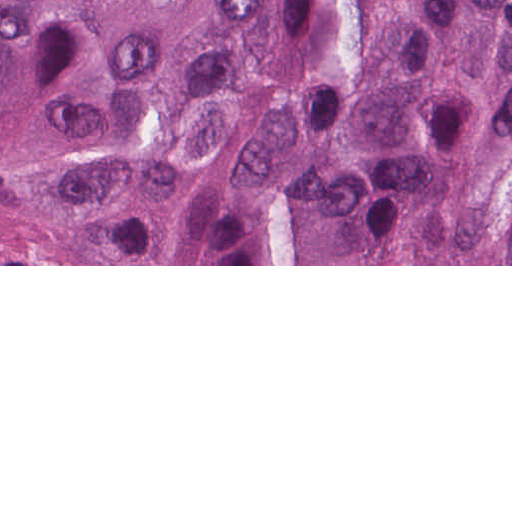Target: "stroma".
I'll list each match as a JSON object with an SVG mask.
<instances>
[{"label": "stroma", "mask_w": 512, "mask_h": 512, "mask_svg": "<svg viewBox=\"0 0 512 512\" xmlns=\"http://www.w3.org/2000/svg\"><path fill=\"white\" fill-rule=\"evenodd\" d=\"M349 0H344V9ZM0 266H512V264H0Z\"/></svg>", "instance_id": "1"}]
</instances>
